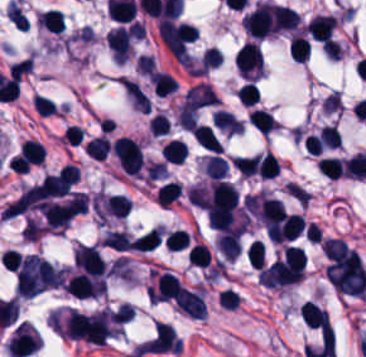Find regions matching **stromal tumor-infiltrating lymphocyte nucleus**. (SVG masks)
<instances>
[{
  "instance_id": "obj_8",
  "label": "stromal tumor-infiltrating lymphocyte nucleus",
  "mask_w": 366,
  "mask_h": 357,
  "mask_svg": "<svg viewBox=\"0 0 366 357\" xmlns=\"http://www.w3.org/2000/svg\"><path fill=\"white\" fill-rule=\"evenodd\" d=\"M248 120L265 136L278 127L272 114L261 108H254L248 116Z\"/></svg>"
},
{
  "instance_id": "obj_6",
  "label": "stromal tumor-infiltrating lymphocyte nucleus",
  "mask_w": 366,
  "mask_h": 357,
  "mask_svg": "<svg viewBox=\"0 0 366 357\" xmlns=\"http://www.w3.org/2000/svg\"><path fill=\"white\" fill-rule=\"evenodd\" d=\"M162 225H154L136 238L133 239L129 246V250L137 252H150L156 247L161 238Z\"/></svg>"
},
{
  "instance_id": "obj_9",
  "label": "stromal tumor-infiltrating lymphocyte nucleus",
  "mask_w": 366,
  "mask_h": 357,
  "mask_svg": "<svg viewBox=\"0 0 366 357\" xmlns=\"http://www.w3.org/2000/svg\"><path fill=\"white\" fill-rule=\"evenodd\" d=\"M194 138L198 144L202 147L212 151L220 152L222 150V145L218 140L217 136L205 125L197 124L192 131Z\"/></svg>"
},
{
  "instance_id": "obj_20",
  "label": "stromal tumor-infiltrating lymphocyte nucleus",
  "mask_w": 366,
  "mask_h": 357,
  "mask_svg": "<svg viewBox=\"0 0 366 357\" xmlns=\"http://www.w3.org/2000/svg\"><path fill=\"white\" fill-rule=\"evenodd\" d=\"M259 96V89L254 82L247 81L238 91V99L246 104L256 103Z\"/></svg>"
},
{
  "instance_id": "obj_4",
  "label": "stromal tumor-infiltrating lymphocyte nucleus",
  "mask_w": 366,
  "mask_h": 357,
  "mask_svg": "<svg viewBox=\"0 0 366 357\" xmlns=\"http://www.w3.org/2000/svg\"><path fill=\"white\" fill-rule=\"evenodd\" d=\"M216 248L226 261H233L241 252L239 234L233 230H227L218 235Z\"/></svg>"
},
{
  "instance_id": "obj_1",
  "label": "stromal tumor-infiltrating lymphocyte nucleus",
  "mask_w": 366,
  "mask_h": 357,
  "mask_svg": "<svg viewBox=\"0 0 366 357\" xmlns=\"http://www.w3.org/2000/svg\"><path fill=\"white\" fill-rule=\"evenodd\" d=\"M110 150L127 175H136L143 166V159L139 145L131 138H118L110 147Z\"/></svg>"
},
{
  "instance_id": "obj_12",
  "label": "stromal tumor-infiltrating lymphocyte nucleus",
  "mask_w": 366,
  "mask_h": 357,
  "mask_svg": "<svg viewBox=\"0 0 366 357\" xmlns=\"http://www.w3.org/2000/svg\"><path fill=\"white\" fill-rule=\"evenodd\" d=\"M159 153L166 162L182 163L186 154V145L183 141L173 138Z\"/></svg>"
},
{
  "instance_id": "obj_2",
  "label": "stromal tumor-infiltrating lymphocyte nucleus",
  "mask_w": 366,
  "mask_h": 357,
  "mask_svg": "<svg viewBox=\"0 0 366 357\" xmlns=\"http://www.w3.org/2000/svg\"><path fill=\"white\" fill-rule=\"evenodd\" d=\"M336 24L335 16L316 15L309 21L306 29L313 40L330 42Z\"/></svg>"
},
{
  "instance_id": "obj_17",
  "label": "stromal tumor-infiltrating lymphocyte nucleus",
  "mask_w": 366,
  "mask_h": 357,
  "mask_svg": "<svg viewBox=\"0 0 366 357\" xmlns=\"http://www.w3.org/2000/svg\"><path fill=\"white\" fill-rule=\"evenodd\" d=\"M204 169L206 175L221 180L227 173V164L220 155H212L205 160Z\"/></svg>"
},
{
  "instance_id": "obj_18",
  "label": "stromal tumor-infiltrating lymphocyte nucleus",
  "mask_w": 366,
  "mask_h": 357,
  "mask_svg": "<svg viewBox=\"0 0 366 357\" xmlns=\"http://www.w3.org/2000/svg\"><path fill=\"white\" fill-rule=\"evenodd\" d=\"M187 258L190 264L206 267L210 264L211 252L210 249L201 243H193L188 252Z\"/></svg>"
},
{
  "instance_id": "obj_15",
  "label": "stromal tumor-infiltrating lymphocyte nucleus",
  "mask_w": 366,
  "mask_h": 357,
  "mask_svg": "<svg viewBox=\"0 0 366 357\" xmlns=\"http://www.w3.org/2000/svg\"><path fill=\"white\" fill-rule=\"evenodd\" d=\"M182 192L181 187L174 181H167L159 186L156 201L161 205H170Z\"/></svg>"
},
{
  "instance_id": "obj_13",
  "label": "stromal tumor-infiltrating lymphocyte nucleus",
  "mask_w": 366,
  "mask_h": 357,
  "mask_svg": "<svg viewBox=\"0 0 366 357\" xmlns=\"http://www.w3.org/2000/svg\"><path fill=\"white\" fill-rule=\"evenodd\" d=\"M308 53L309 44L305 38L298 35H291L288 46V56L290 59L302 64L308 57Z\"/></svg>"
},
{
  "instance_id": "obj_3",
  "label": "stromal tumor-infiltrating lymphocyte nucleus",
  "mask_w": 366,
  "mask_h": 357,
  "mask_svg": "<svg viewBox=\"0 0 366 357\" xmlns=\"http://www.w3.org/2000/svg\"><path fill=\"white\" fill-rule=\"evenodd\" d=\"M299 316L308 326L330 331L327 311L308 300L299 307Z\"/></svg>"
},
{
  "instance_id": "obj_10",
  "label": "stromal tumor-infiltrating lymphocyte nucleus",
  "mask_w": 366,
  "mask_h": 357,
  "mask_svg": "<svg viewBox=\"0 0 366 357\" xmlns=\"http://www.w3.org/2000/svg\"><path fill=\"white\" fill-rule=\"evenodd\" d=\"M110 151L107 137L95 136L85 146L84 152L91 160H105Z\"/></svg>"
},
{
  "instance_id": "obj_19",
  "label": "stromal tumor-infiltrating lymphocyte nucleus",
  "mask_w": 366,
  "mask_h": 357,
  "mask_svg": "<svg viewBox=\"0 0 366 357\" xmlns=\"http://www.w3.org/2000/svg\"><path fill=\"white\" fill-rule=\"evenodd\" d=\"M282 260L284 264L302 269L304 265V253L298 247L286 246L283 250Z\"/></svg>"
},
{
  "instance_id": "obj_14",
  "label": "stromal tumor-infiltrating lymphocyte nucleus",
  "mask_w": 366,
  "mask_h": 357,
  "mask_svg": "<svg viewBox=\"0 0 366 357\" xmlns=\"http://www.w3.org/2000/svg\"><path fill=\"white\" fill-rule=\"evenodd\" d=\"M5 16L9 19L14 28L26 30L29 21L16 1H9L5 7Z\"/></svg>"
},
{
  "instance_id": "obj_5",
  "label": "stromal tumor-infiltrating lymphocyte nucleus",
  "mask_w": 366,
  "mask_h": 357,
  "mask_svg": "<svg viewBox=\"0 0 366 357\" xmlns=\"http://www.w3.org/2000/svg\"><path fill=\"white\" fill-rule=\"evenodd\" d=\"M270 13L273 27L277 32L294 28L299 22L298 15L287 6L272 4Z\"/></svg>"
},
{
  "instance_id": "obj_21",
  "label": "stromal tumor-infiltrating lymphocyte nucleus",
  "mask_w": 366,
  "mask_h": 357,
  "mask_svg": "<svg viewBox=\"0 0 366 357\" xmlns=\"http://www.w3.org/2000/svg\"><path fill=\"white\" fill-rule=\"evenodd\" d=\"M287 192L290 196H292L297 202L301 205L307 204L309 200L308 192L304 188L298 186L295 183L289 182L286 185Z\"/></svg>"
},
{
  "instance_id": "obj_16",
  "label": "stromal tumor-infiltrating lymphocyte nucleus",
  "mask_w": 366,
  "mask_h": 357,
  "mask_svg": "<svg viewBox=\"0 0 366 357\" xmlns=\"http://www.w3.org/2000/svg\"><path fill=\"white\" fill-rule=\"evenodd\" d=\"M317 168L326 176L338 179L343 173L341 159L335 157H321L317 161Z\"/></svg>"
},
{
  "instance_id": "obj_11",
  "label": "stromal tumor-infiltrating lymphocyte nucleus",
  "mask_w": 366,
  "mask_h": 357,
  "mask_svg": "<svg viewBox=\"0 0 366 357\" xmlns=\"http://www.w3.org/2000/svg\"><path fill=\"white\" fill-rule=\"evenodd\" d=\"M130 239L126 232L121 230H108L101 238V247L125 252Z\"/></svg>"
},
{
  "instance_id": "obj_7",
  "label": "stromal tumor-infiltrating lymphocyte nucleus",
  "mask_w": 366,
  "mask_h": 357,
  "mask_svg": "<svg viewBox=\"0 0 366 357\" xmlns=\"http://www.w3.org/2000/svg\"><path fill=\"white\" fill-rule=\"evenodd\" d=\"M40 27L48 32H63L66 27L64 16L61 10L48 8L42 12L37 19Z\"/></svg>"
}]
</instances>
